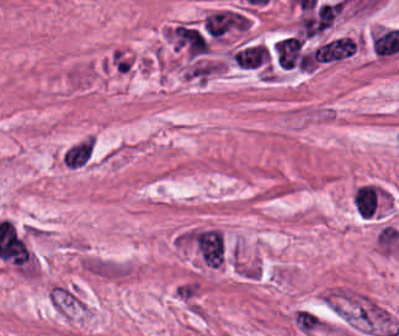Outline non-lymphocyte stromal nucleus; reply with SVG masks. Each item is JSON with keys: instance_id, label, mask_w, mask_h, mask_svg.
<instances>
[{"instance_id": "1", "label": "non-lymphocyte stromal nucleus", "mask_w": 399, "mask_h": 336, "mask_svg": "<svg viewBox=\"0 0 399 336\" xmlns=\"http://www.w3.org/2000/svg\"><path fill=\"white\" fill-rule=\"evenodd\" d=\"M338 318L370 336H396L399 321L376 299L358 290H338L323 298Z\"/></svg>"}, {"instance_id": "2", "label": "non-lymphocyte stromal nucleus", "mask_w": 399, "mask_h": 336, "mask_svg": "<svg viewBox=\"0 0 399 336\" xmlns=\"http://www.w3.org/2000/svg\"><path fill=\"white\" fill-rule=\"evenodd\" d=\"M273 56L278 67L288 70L310 69V57L302 37L284 36L274 46Z\"/></svg>"}, {"instance_id": "3", "label": "non-lymphocyte stromal nucleus", "mask_w": 399, "mask_h": 336, "mask_svg": "<svg viewBox=\"0 0 399 336\" xmlns=\"http://www.w3.org/2000/svg\"><path fill=\"white\" fill-rule=\"evenodd\" d=\"M202 22L212 38H222L244 30L249 23L245 13L237 9L211 11Z\"/></svg>"}, {"instance_id": "4", "label": "non-lymphocyte stromal nucleus", "mask_w": 399, "mask_h": 336, "mask_svg": "<svg viewBox=\"0 0 399 336\" xmlns=\"http://www.w3.org/2000/svg\"><path fill=\"white\" fill-rule=\"evenodd\" d=\"M342 10V1H326L301 18L300 33L312 37L329 26Z\"/></svg>"}, {"instance_id": "5", "label": "non-lymphocyte stromal nucleus", "mask_w": 399, "mask_h": 336, "mask_svg": "<svg viewBox=\"0 0 399 336\" xmlns=\"http://www.w3.org/2000/svg\"><path fill=\"white\" fill-rule=\"evenodd\" d=\"M96 140L84 135L64 147L59 159L67 169H81L89 166L95 156Z\"/></svg>"}, {"instance_id": "6", "label": "non-lymphocyte stromal nucleus", "mask_w": 399, "mask_h": 336, "mask_svg": "<svg viewBox=\"0 0 399 336\" xmlns=\"http://www.w3.org/2000/svg\"><path fill=\"white\" fill-rule=\"evenodd\" d=\"M231 59L241 69H263L270 62V50L266 45L246 43L235 49Z\"/></svg>"}, {"instance_id": "7", "label": "non-lymphocyte stromal nucleus", "mask_w": 399, "mask_h": 336, "mask_svg": "<svg viewBox=\"0 0 399 336\" xmlns=\"http://www.w3.org/2000/svg\"><path fill=\"white\" fill-rule=\"evenodd\" d=\"M355 52L352 37H338L315 48L316 62H331L349 57Z\"/></svg>"}, {"instance_id": "8", "label": "non-lymphocyte stromal nucleus", "mask_w": 399, "mask_h": 336, "mask_svg": "<svg viewBox=\"0 0 399 336\" xmlns=\"http://www.w3.org/2000/svg\"><path fill=\"white\" fill-rule=\"evenodd\" d=\"M296 331L304 336H312L322 327L323 317L312 309L299 307L291 314Z\"/></svg>"}, {"instance_id": "9", "label": "non-lymphocyte stromal nucleus", "mask_w": 399, "mask_h": 336, "mask_svg": "<svg viewBox=\"0 0 399 336\" xmlns=\"http://www.w3.org/2000/svg\"><path fill=\"white\" fill-rule=\"evenodd\" d=\"M179 42L193 55L207 51L206 40L194 27L179 25Z\"/></svg>"}]
</instances>
